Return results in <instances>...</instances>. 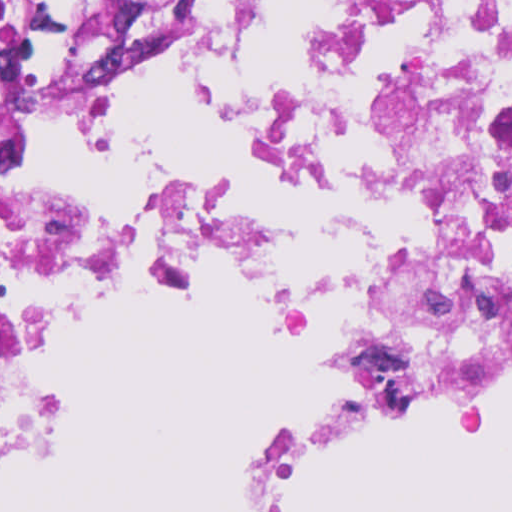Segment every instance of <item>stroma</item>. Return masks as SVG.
Listing matches in <instances>:
<instances>
[{
    "mask_svg": "<svg viewBox=\"0 0 512 512\" xmlns=\"http://www.w3.org/2000/svg\"><path fill=\"white\" fill-rule=\"evenodd\" d=\"M233 1L187 0V12L161 33L101 62L115 71L121 79L125 91L148 73L172 62L194 40L201 28L222 16ZM113 279H203L227 283L256 292L278 309L292 343L314 378L316 384L310 400L353 357L271 292L205 276L183 274L176 269L126 257L41 276L23 319L41 353L50 321L68 303L84 292ZM354 449L327 454L307 466L284 497L306 485L329 465ZM11 452L0 459V464L8 459Z\"/></svg>",
    "mask_w": 512,
    "mask_h": 512,
    "instance_id": "35a3bbf8",
    "label": "stroma"
}]
</instances>
